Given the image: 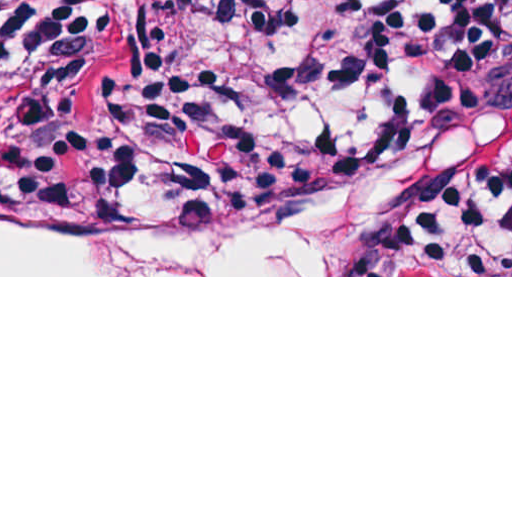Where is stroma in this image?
<instances>
[{"label":"stroma","instance_id":"obj_1","mask_svg":"<svg viewBox=\"0 0 512 512\" xmlns=\"http://www.w3.org/2000/svg\"><path fill=\"white\" fill-rule=\"evenodd\" d=\"M69 92V91H68ZM447 186L423 169L354 175L270 219L234 227L264 232H370L407 261L404 276H0V277H512L453 275L414 237L435 216ZM0 196L25 212L71 221H193L135 212L60 194L32 177L0 175Z\"/></svg>","mask_w":512,"mask_h":512}]
</instances>
